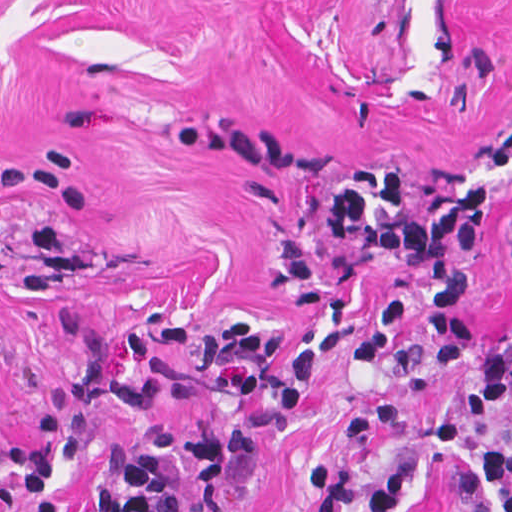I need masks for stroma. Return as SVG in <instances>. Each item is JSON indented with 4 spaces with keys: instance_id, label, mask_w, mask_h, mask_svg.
<instances>
[{
    "instance_id": "35a3bbf8",
    "label": "stroma",
    "mask_w": 512,
    "mask_h": 512,
    "mask_svg": "<svg viewBox=\"0 0 512 512\" xmlns=\"http://www.w3.org/2000/svg\"><path fill=\"white\" fill-rule=\"evenodd\" d=\"M512 0H0V512H28L9 455L42 398L73 431L203 425L240 407L236 370L159 334L187 320L272 327L324 380L276 412L255 459L228 461L221 512H317L311 468L375 474L415 459L413 512H505L479 448L512 451V399L478 410L470 378L430 367L412 314L365 369L343 353L376 295L407 285L336 239L335 197L402 164L428 212L479 181L494 195L467 298L496 340L512 325ZM178 512H211L168 473ZM83 454L58 512H93Z\"/></svg>"
}]
</instances>
